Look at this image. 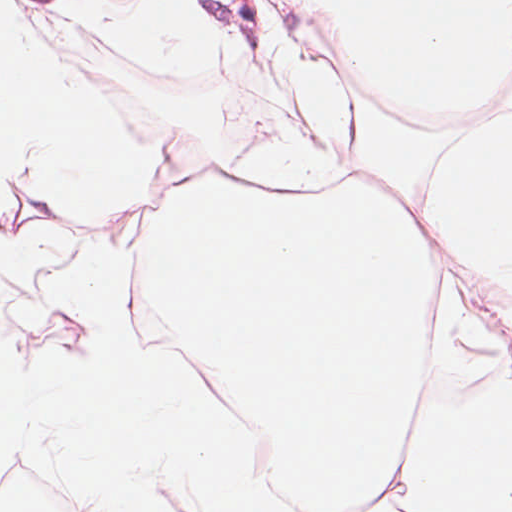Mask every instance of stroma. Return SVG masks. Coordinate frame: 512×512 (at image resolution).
Wrapping results in <instances>:
<instances>
[{
    "label": "stroma",
    "mask_w": 512,
    "mask_h": 512,
    "mask_svg": "<svg viewBox=\"0 0 512 512\" xmlns=\"http://www.w3.org/2000/svg\"><path fill=\"white\" fill-rule=\"evenodd\" d=\"M115 0H14L27 26L46 52L58 59L70 80L97 97L98 37ZM219 47L241 54L293 51L314 40L289 9L276 0H194ZM355 113L372 122L390 145L441 142V174L429 214L411 202L433 255L435 282L448 293L476 340L512 347V291L459 257L436 215L448 172L462 150L485 130L512 129V76L496 100L461 120L425 123L371 100L357 77ZM435 140H427L419 137ZM229 176L187 172L160 153L154 197L141 215L119 227L75 215L35 187L0 173V239L9 240L38 224L137 254L144 227L170 197ZM349 181H359L353 161ZM297 194H321L306 188ZM123 249L124 264L135 257Z\"/></svg>",
    "instance_id": "stroma-1"
}]
</instances>
